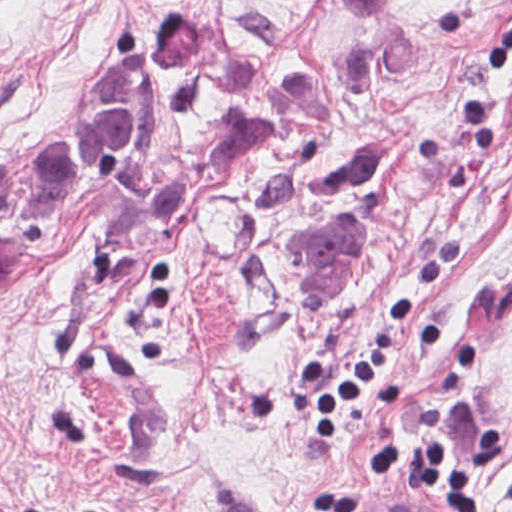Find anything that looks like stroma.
<instances>
[{
	"instance_id": "obj_1",
	"label": "stroma",
	"mask_w": 512,
	"mask_h": 512,
	"mask_svg": "<svg viewBox=\"0 0 512 512\" xmlns=\"http://www.w3.org/2000/svg\"><path fill=\"white\" fill-rule=\"evenodd\" d=\"M215 22L201 74L148 88L136 38ZM512 0H403L380 27L299 0H0V512L355 511L432 499L497 430L512 512ZM414 321L329 438L302 366ZM399 440V470H370ZM354 511V512H355Z\"/></svg>"
}]
</instances>
